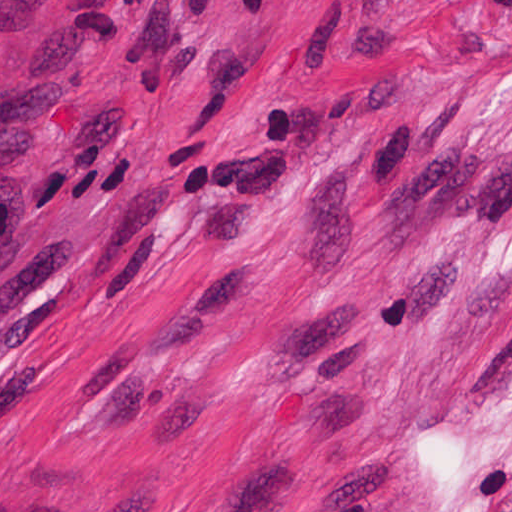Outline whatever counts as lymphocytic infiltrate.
Masks as SVG:
<instances>
[{
  "label": "lymphocytic infiltrate",
  "mask_w": 512,
  "mask_h": 512,
  "mask_svg": "<svg viewBox=\"0 0 512 512\" xmlns=\"http://www.w3.org/2000/svg\"><path fill=\"white\" fill-rule=\"evenodd\" d=\"M23 222V197L0 176V269L20 234Z\"/></svg>",
  "instance_id": "f902f5d3"
}]
</instances>
